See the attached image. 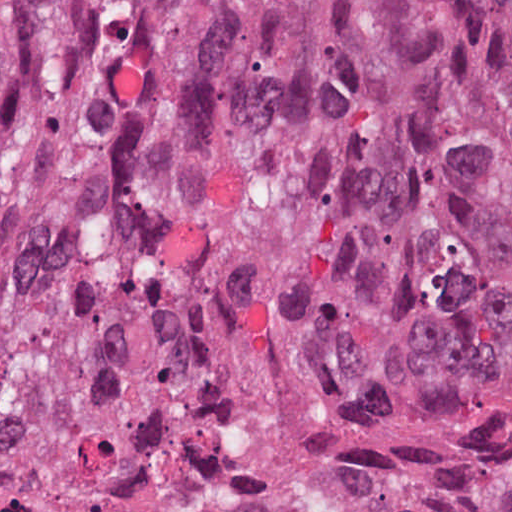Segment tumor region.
Listing matches in <instances>:
<instances>
[{
  "mask_svg": "<svg viewBox=\"0 0 512 512\" xmlns=\"http://www.w3.org/2000/svg\"><path fill=\"white\" fill-rule=\"evenodd\" d=\"M511 287L512 0H55L0 97V488L140 494ZM239 512H512V356Z\"/></svg>",
  "mask_w": 512,
  "mask_h": 512,
  "instance_id": "obj_1",
  "label": "tumor region"
}]
</instances>
